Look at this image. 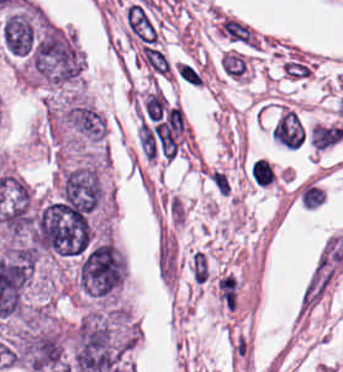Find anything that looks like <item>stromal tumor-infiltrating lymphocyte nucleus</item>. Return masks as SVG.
<instances>
[{
  "label": "stromal tumor-infiltrating lymphocyte nucleus",
  "instance_id": "bc302bb0",
  "mask_svg": "<svg viewBox=\"0 0 343 372\" xmlns=\"http://www.w3.org/2000/svg\"><path fill=\"white\" fill-rule=\"evenodd\" d=\"M249 170L254 184L268 185L272 182L271 169L266 160H255L252 162Z\"/></svg>",
  "mask_w": 343,
  "mask_h": 372
}]
</instances>
